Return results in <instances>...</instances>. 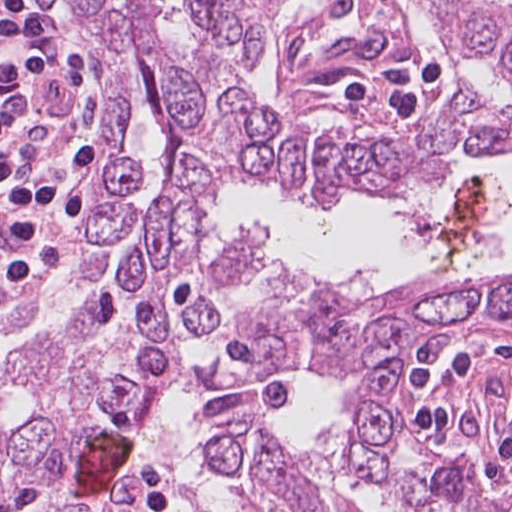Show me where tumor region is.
<instances>
[{"instance_id": "1", "label": "tumor region", "mask_w": 512, "mask_h": 512, "mask_svg": "<svg viewBox=\"0 0 512 512\" xmlns=\"http://www.w3.org/2000/svg\"><path fill=\"white\" fill-rule=\"evenodd\" d=\"M451 323H512V290L215 386L197 417L196 441L210 473L242 512H363L334 476L279 432L287 403L277 371L354 369ZM399 363L388 361L348 392L332 460L347 475L378 477L422 512H481L482 482L468 473L396 478L388 452L400 430L393 402ZM167 402L0 456V512H156L175 502L193 512L183 482L162 451ZM128 434L127 460L85 495L78 452L91 436ZM490 512H512V480Z\"/></svg>"}]
</instances>
